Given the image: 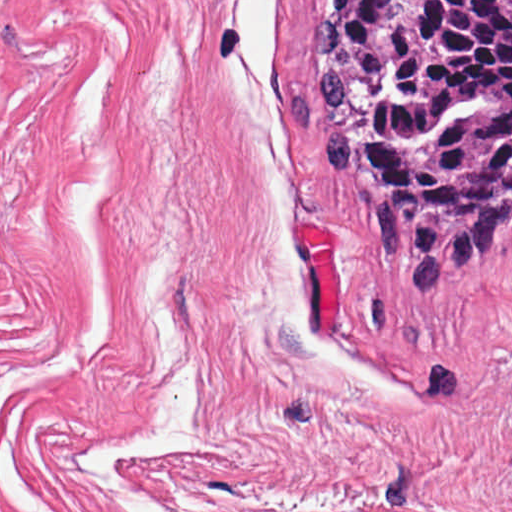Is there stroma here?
<instances>
[{"label":"stroma","mask_w":512,"mask_h":512,"mask_svg":"<svg viewBox=\"0 0 512 512\" xmlns=\"http://www.w3.org/2000/svg\"><path fill=\"white\" fill-rule=\"evenodd\" d=\"M317 3L143 0L97 449L193 360L195 450L127 477L163 512H512V225L439 298L380 240Z\"/></svg>","instance_id":"stroma-1"}]
</instances>
